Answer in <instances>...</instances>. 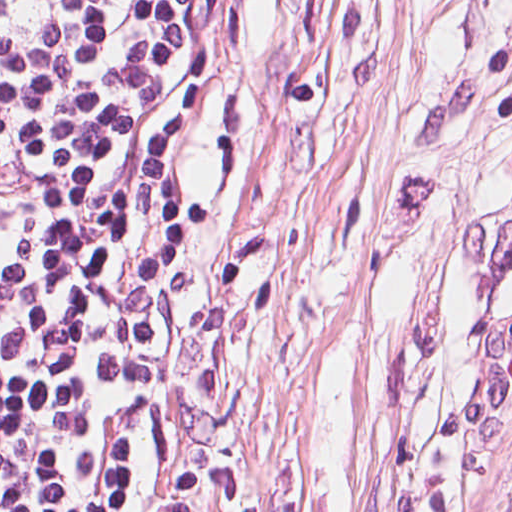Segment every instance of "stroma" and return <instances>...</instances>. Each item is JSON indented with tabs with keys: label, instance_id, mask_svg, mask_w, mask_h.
<instances>
[{
	"label": "stroma",
	"instance_id": "35a3bbf8",
	"mask_svg": "<svg viewBox=\"0 0 512 512\" xmlns=\"http://www.w3.org/2000/svg\"><path fill=\"white\" fill-rule=\"evenodd\" d=\"M172 153L168 512H512V0H225Z\"/></svg>",
	"mask_w": 512,
	"mask_h": 512
}]
</instances>
